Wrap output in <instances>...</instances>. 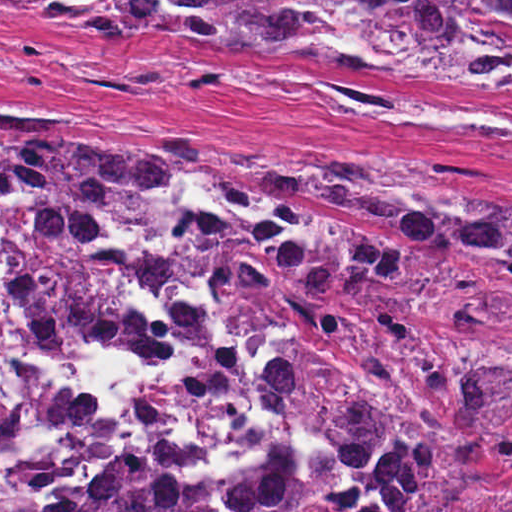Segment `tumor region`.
I'll use <instances>...</instances> for the list:
<instances>
[{
    "mask_svg": "<svg viewBox=\"0 0 512 512\" xmlns=\"http://www.w3.org/2000/svg\"><path fill=\"white\" fill-rule=\"evenodd\" d=\"M90 37L153 34L268 49L495 93L512 88V0H0ZM92 12L106 19L73 13ZM63 119L52 125L59 124ZM186 145L134 121L0 128V193L102 222L191 206L212 329L263 417L258 468L181 486L101 464L62 512H329L300 438L334 462L350 512H512V188L242 145ZM29 361L0 350V458L45 421Z\"/></svg>",
    "mask_w": 512,
    "mask_h": 512,
    "instance_id": "tumor-region-1",
    "label": "tumor region"
}]
</instances>
